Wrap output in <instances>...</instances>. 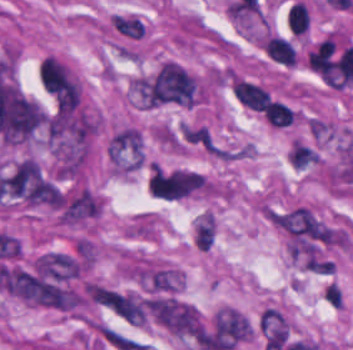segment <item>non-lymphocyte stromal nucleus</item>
<instances>
[{
    "label": "non-lymphocyte stromal nucleus",
    "instance_id": "a72fc3eb",
    "mask_svg": "<svg viewBox=\"0 0 353 350\" xmlns=\"http://www.w3.org/2000/svg\"><path fill=\"white\" fill-rule=\"evenodd\" d=\"M146 305L154 320L171 334L181 337L201 331L198 312L190 304L171 297H151Z\"/></svg>",
    "mask_w": 353,
    "mask_h": 350
},
{
    "label": "non-lymphocyte stromal nucleus",
    "instance_id": "81446118",
    "mask_svg": "<svg viewBox=\"0 0 353 350\" xmlns=\"http://www.w3.org/2000/svg\"><path fill=\"white\" fill-rule=\"evenodd\" d=\"M56 212L61 222L76 225L97 216L98 200L92 192L83 188L65 195L59 201Z\"/></svg>",
    "mask_w": 353,
    "mask_h": 350
},
{
    "label": "non-lymphocyte stromal nucleus",
    "instance_id": "7c5642bf",
    "mask_svg": "<svg viewBox=\"0 0 353 350\" xmlns=\"http://www.w3.org/2000/svg\"><path fill=\"white\" fill-rule=\"evenodd\" d=\"M107 152L110 160L116 163L142 164L141 133L134 127H121L108 141Z\"/></svg>",
    "mask_w": 353,
    "mask_h": 350
},
{
    "label": "non-lymphocyte stromal nucleus",
    "instance_id": "dd21d789",
    "mask_svg": "<svg viewBox=\"0 0 353 350\" xmlns=\"http://www.w3.org/2000/svg\"><path fill=\"white\" fill-rule=\"evenodd\" d=\"M1 286L11 295L37 305H63L64 289L37 274L17 267L5 270Z\"/></svg>",
    "mask_w": 353,
    "mask_h": 350
},
{
    "label": "non-lymphocyte stromal nucleus",
    "instance_id": "fc2b8d12",
    "mask_svg": "<svg viewBox=\"0 0 353 350\" xmlns=\"http://www.w3.org/2000/svg\"><path fill=\"white\" fill-rule=\"evenodd\" d=\"M251 325L211 321L205 326L197 339L199 349L227 350L245 341Z\"/></svg>",
    "mask_w": 353,
    "mask_h": 350
},
{
    "label": "non-lymphocyte stromal nucleus",
    "instance_id": "9d01c50a",
    "mask_svg": "<svg viewBox=\"0 0 353 350\" xmlns=\"http://www.w3.org/2000/svg\"><path fill=\"white\" fill-rule=\"evenodd\" d=\"M259 327L265 342L285 343L288 336L287 322L282 314L272 307L262 310Z\"/></svg>",
    "mask_w": 353,
    "mask_h": 350
},
{
    "label": "non-lymphocyte stromal nucleus",
    "instance_id": "3746e769",
    "mask_svg": "<svg viewBox=\"0 0 353 350\" xmlns=\"http://www.w3.org/2000/svg\"><path fill=\"white\" fill-rule=\"evenodd\" d=\"M39 76L57 106L77 108L81 102V89L66 66L56 58L46 57Z\"/></svg>",
    "mask_w": 353,
    "mask_h": 350
}]
</instances>
